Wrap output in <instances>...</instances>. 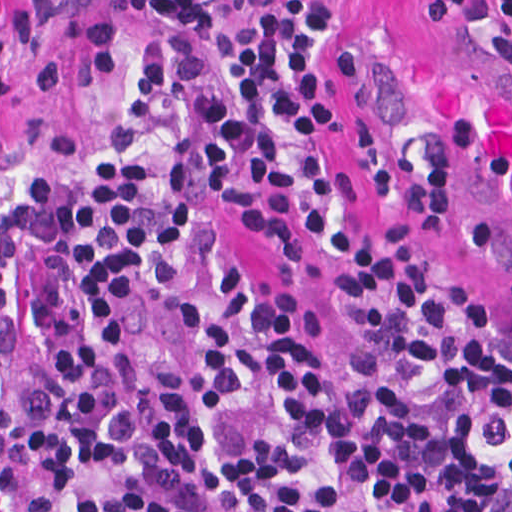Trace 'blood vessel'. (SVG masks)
Instances as JSON below:
<instances>
[{"instance_id":"obj_1","label":"blood vessel","mask_w":512,"mask_h":512,"mask_svg":"<svg viewBox=\"0 0 512 512\" xmlns=\"http://www.w3.org/2000/svg\"><path fill=\"white\" fill-rule=\"evenodd\" d=\"M512 59L345 52V83L436 208L512 284Z\"/></svg>"}]
</instances>
